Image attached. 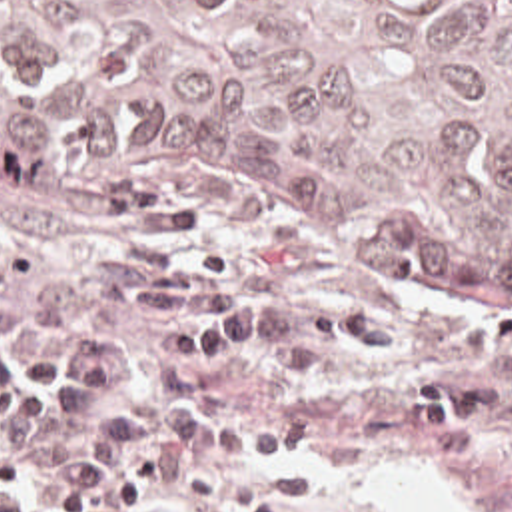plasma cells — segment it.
<instances>
[{
    "label": "plasma cells",
    "mask_w": 512,
    "mask_h": 512,
    "mask_svg": "<svg viewBox=\"0 0 512 512\" xmlns=\"http://www.w3.org/2000/svg\"><path fill=\"white\" fill-rule=\"evenodd\" d=\"M0 512H34V501L16 493L0 491Z\"/></svg>",
    "instance_id": "plasma-cells-1"
}]
</instances>
